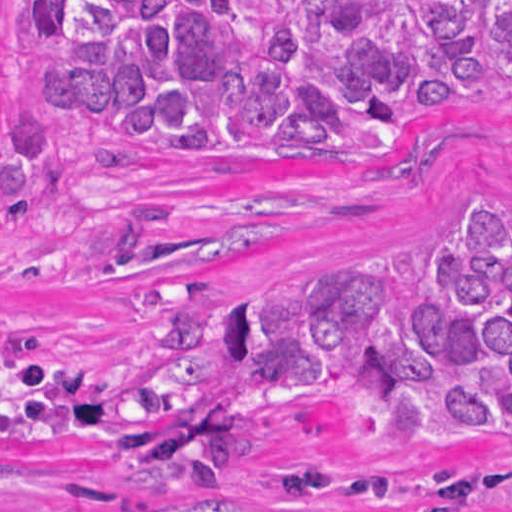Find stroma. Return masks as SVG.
Segmentation results:
<instances>
[{"label": "stroma", "mask_w": 512, "mask_h": 512, "mask_svg": "<svg viewBox=\"0 0 512 512\" xmlns=\"http://www.w3.org/2000/svg\"><path fill=\"white\" fill-rule=\"evenodd\" d=\"M0 92L39 107L30 21L0 0ZM75 154L67 188L32 219L0 226V320L30 329L60 355L124 367L158 347L166 310L146 287L193 279L204 305L255 297L321 265L412 249L417 279L443 232L471 203L512 206V95L461 106L370 164L169 161L125 136L52 119ZM151 284V285H148ZM457 453H369L347 409L270 413L237 484L144 488L127 455L88 441L0 445V506L69 512H414L389 500L298 502L276 492L286 462L335 467L430 465L512 475V441ZM482 512H512V489Z\"/></svg>", "instance_id": "stroma-1"}]
</instances>
